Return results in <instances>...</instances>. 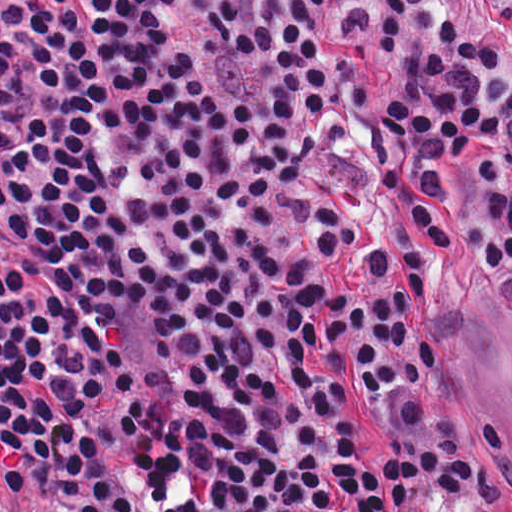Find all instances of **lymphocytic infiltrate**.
I'll return each instance as SVG.
<instances>
[{
  "instance_id": "lymphocytic-infiltrate-1",
  "label": "lymphocytic infiltrate",
  "mask_w": 512,
  "mask_h": 512,
  "mask_svg": "<svg viewBox=\"0 0 512 512\" xmlns=\"http://www.w3.org/2000/svg\"><path fill=\"white\" fill-rule=\"evenodd\" d=\"M330 0L0 147V512H466L429 282L512 266V68ZM512 21V0H486Z\"/></svg>"
}]
</instances>
